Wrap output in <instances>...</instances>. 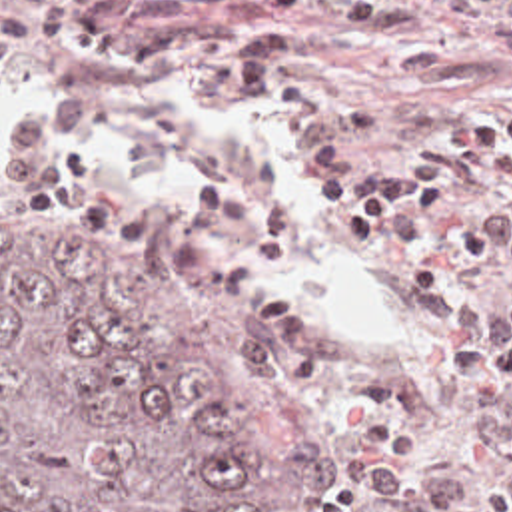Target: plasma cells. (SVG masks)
Segmentation results:
<instances>
[{
	"instance_id": "1",
	"label": "plasma cells",
	"mask_w": 512,
	"mask_h": 512,
	"mask_svg": "<svg viewBox=\"0 0 512 512\" xmlns=\"http://www.w3.org/2000/svg\"><path fill=\"white\" fill-rule=\"evenodd\" d=\"M230 0H0V56L70 52L118 70H182L226 50L180 24ZM345 16L385 38L413 26L399 0H253ZM239 102L329 130L307 152L323 226L383 319L343 339L313 307V244L293 208L247 178L202 192L194 263L241 309L273 371L313 401L353 475L347 512H512V106L471 110L445 148L365 152L335 126L321 40L273 26L214 82L106 96L36 86L0 68V208L98 226H148L152 206L82 154L96 130L172 146Z\"/></svg>"
}]
</instances>
